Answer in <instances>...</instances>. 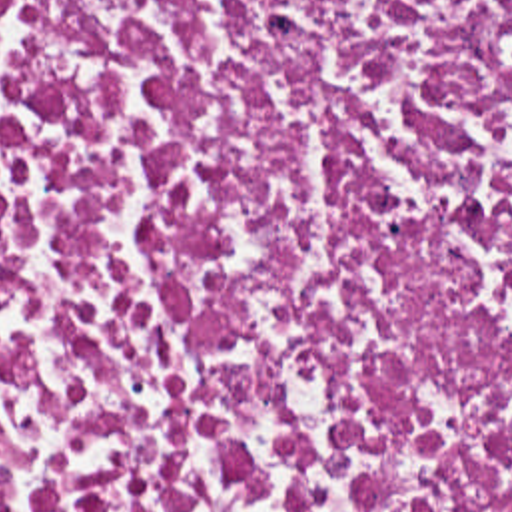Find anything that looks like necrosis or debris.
I'll use <instances>...</instances> for the list:
<instances>
[{
    "instance_id": "1",
    "label": "necrosis or debris",
    "mask_w": 512,
    "mask_h": 512,
    "mask_svg": "<svg viewBox=\"0 0 512 512\" xmlns=\"http://www.w3.org/2000/svg\"><path fill=\"white\" fill-rule=\"evenodd\" d=\"M0 512H512V0H0Z\"/></svg>"
}]
</instances>
